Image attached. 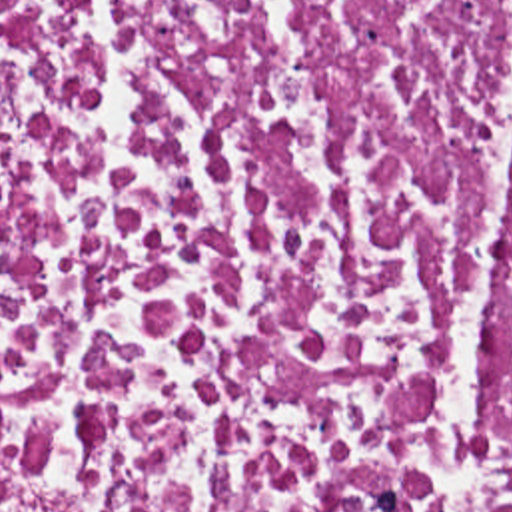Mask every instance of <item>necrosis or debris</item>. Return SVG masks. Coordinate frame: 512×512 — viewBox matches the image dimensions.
Returning a JSON list of instances; mask_svg holds the SVG:
<instances>
[{"label":"necrosis or debris","instance_id":"1","mask_svg":"<svg viewBox=\"0 0 512 512\" xmlns=\"http://www.w3.org/2000/svg\"><path fill=\"white\" fill-rule=\"evenodd\" d=\"M0 512H512V0H0Z\"/></svg>","mask_w":512,"mask_h":512}]
</instances>
